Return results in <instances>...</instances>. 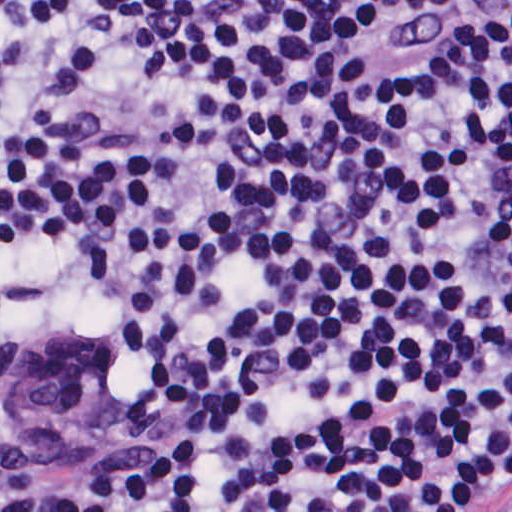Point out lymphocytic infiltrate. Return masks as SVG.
Instances as JSON below:
<instances>
[{
	"label": "lymphocytic infiltrate",
	"mask_w": 512,
	"mask_h": 512,
	"mask_svg": "<svg viewBox=\"0 0 512 512\" xmlns=\"http://www.w3.org/2000/svg\"><path fill=\"white\" fill-rule=\"evenodd\" d=\"M0 324L143 400L0 512H512V0H0Z\"/></svg>",
	"instance_id": "1"
}]
</instances>
